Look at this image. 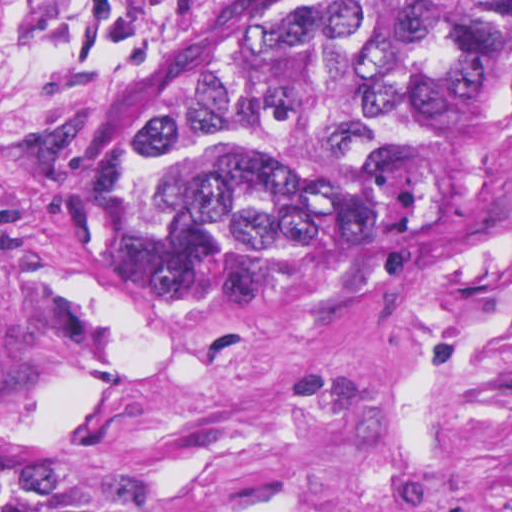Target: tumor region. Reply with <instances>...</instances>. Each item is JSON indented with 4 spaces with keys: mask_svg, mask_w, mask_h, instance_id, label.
I'll use <instances>...</instances> for the list:
<instances>
[{
    "mask_svg": "<svg viewBox=\"0 0 512 512\" xmlns=\"http://www.w3.org/2000/svg\"><path fill=\"white\" fill-rule=\"evenodd\" d=\"M512 123V0H253L111 103L131 265L392 271ZM0 512H133L0 387Z\"/></svg>",
    "mask_w": 512,
    "mask_h": 512,
    "instance_id": "obj_1",
    "label": "tumor region"
}]
</instances>
